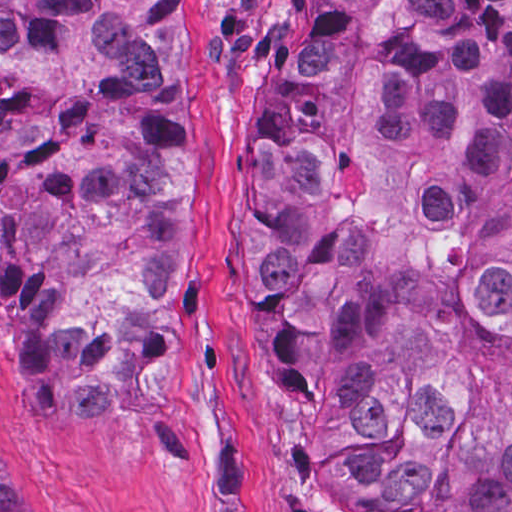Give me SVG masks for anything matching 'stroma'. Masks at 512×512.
I'll return each mask as SVG.
<instances>
[{
	"label": "stroma",
	"mask_w": 512,
	"mask_h": 512,
	"mask_svg": "<svg viewBox=\"0 0 512 512\" xmlns=\"http://www.w3.org/2000/svg\"><path fill=\"white\" fill-rule=\"evenodd\" d=\"M324 3L188 1L186 248L151 414L35 418L0 297V442L27 512H369L321 488L305 421L257 369L243 317L252 120Z\"/></svg>",
	"instance_id": "stroma-1"
}]
</instances>
